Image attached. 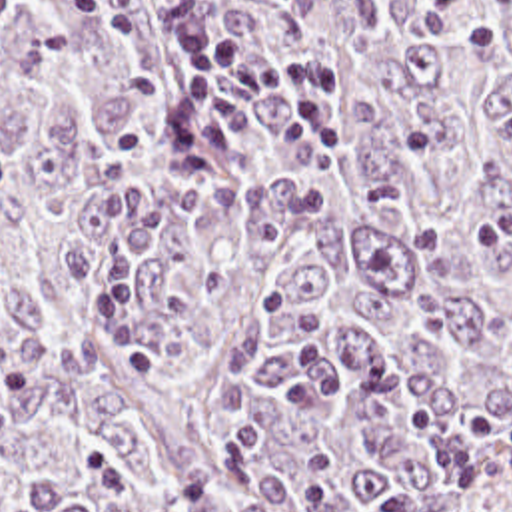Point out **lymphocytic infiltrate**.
<instances>
[{"label":"lymphocytic infiltrate","mask_w":512,"mask_h":512,"mask_svg":"<svg viewBox=\"0 0 512 512\" xmlns=\"http://www.w3.org/2000/svg\"><path fill=\"white\" fill-rule=\"evenodd\" d=\"M185 0H145L151 28L185 58L183 96L167 132V150L187 176L207 174L229 162L249 132L243 110L253 90H267L291 114L279 150L303 172L333 164L345 154V126L333 106L329 78L311 60L271 66L249 58L239 40L185 18Z\"/></svg>","instance_id":"lymphocytic-infiltrate-1"}]
</instances>
